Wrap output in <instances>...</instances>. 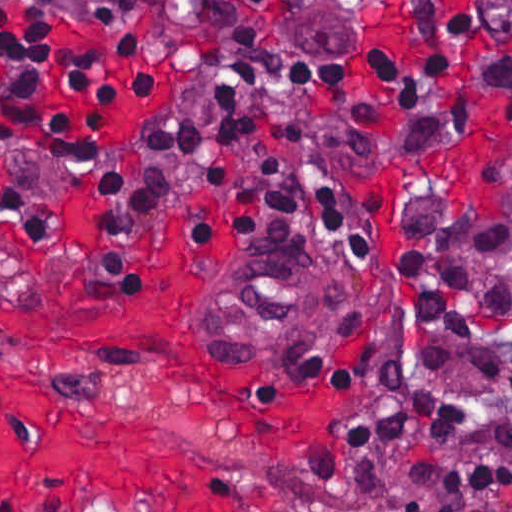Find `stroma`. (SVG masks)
<instances>
[{"mask_svg":"<svg viewBox=\"0 0 512 512\" xmlns=\"http://www.w3.org/2000/svg\"><path fill=\"white\" fill-rule=\"evenodd\" d=\"M230 24L276 55L306 95L287 97L284 111L317 144L339 184L358 200L381 206V273L346 284L337 295L330 334L304 348H243L215 329L210 315L214 275L237 253L263 251L285 239L335 256L326 242L293 228H262L211 256H194V218L218 217L230 191L210 168L218 161L257 167L246 145H205L179 162L162 194L160 213L128 257L133 287L90 280L100 242L97 205L89 186L110 153L137 140L156 115L179 97L184 114L206 120L218 101L211 95L218 41L193 31L173 13L148 3L140 25L150 46L153 90L143 103L115 108L106 136L86 169L66 171L47 159L12 152L0 159V194L33 190L62 209V219L42 249L8 243L11 226L0 215V274L65 283L112 304L167 307L162 324L142 338L75 340L7 331L10 362L50 379L111 420L184 452L217 460L244 483V512H402L388 496L372 504L332 495L318 476L332 456L338 421L367 396L383 367L397 359L411 379L432 392L468 405L455 442L418 439L386 449L380 478L396 503L425 499L437 512L433 492L412 478L414 466L432 456L480 454L512 461L495 427L512 417V392L478 374L483 349L427 331L423 346L447 347L440 368L420 365L394 296V246L399 212L413 197L467 192L493 213L512 193V49L462 14L442 7L385 26L383 42L368 66L325 75L292 60L251 0H169ZM449 49L487 68L442 80L432 102L417 110L395 109L386 90L380 99V139L373 152L347 157L341 110L325 99L381 70ZM427 123L444 135L417 156L401 159L408 131ZM335 261V257L329 258ZM347 288V290H346ZM485 342L512 359V323L489 332ZM315 489V490H314ZM184 512H194L177 507ZM49 512H178L141 497L107 491L75 493ZM470 512H512V495L479 501Z\"/></svg>","mask_w":512,"mask_h":512,"instance_id":"stroma-1","label":"stroma"}]
</instances>
